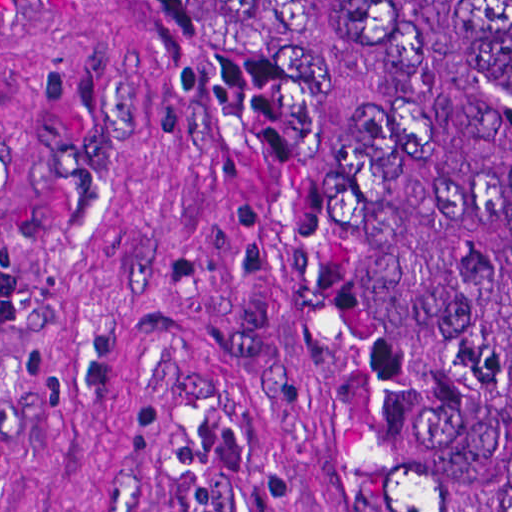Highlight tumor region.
I'll return each mask as SVG.
<instances>
[{"label": "tumor region", "mask_w": 512, "mask_h": 512, "mask_svg": "<svg viewBox=\"0 0 512 512\" xmlns=\"http://www.w3.org/2000/svg\"><path fill=\"white\" fill-rule=\"evenodd\" d=\"M161 47L269 179L402 512H512V0H0Z\"/></svg>", "instance_id": "tumor-region-1"}]
</instances>
